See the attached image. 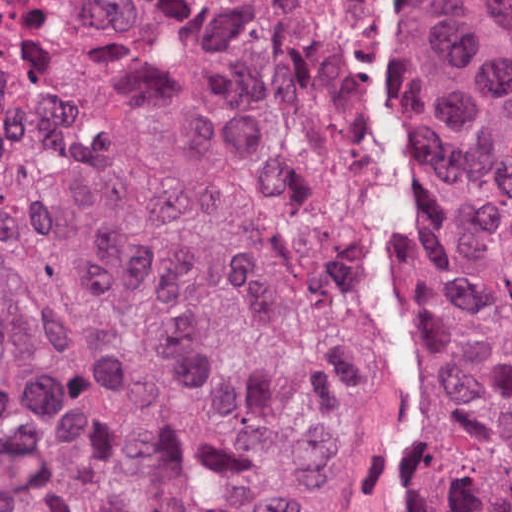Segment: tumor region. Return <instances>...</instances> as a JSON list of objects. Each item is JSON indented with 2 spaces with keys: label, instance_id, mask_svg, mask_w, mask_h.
I'll return each instance as SVG.
<instances>
[{
  "label": "tumor region",
  "instance_id": "obj_1",
  "mask_svg": "<svg viewBox=\"0 0 512 512\" xmlns=\"http://www.w3.org/2000/svg\"><path fill=\"white\" fill-rule=\"evenodd\" d=\"M421 411L512 512V75L392 0ZM350 0H0V512H404L348 260Z\"/></svg>",
  "mask_w": 512,
  "mask_h": 512
}]
</instances>
